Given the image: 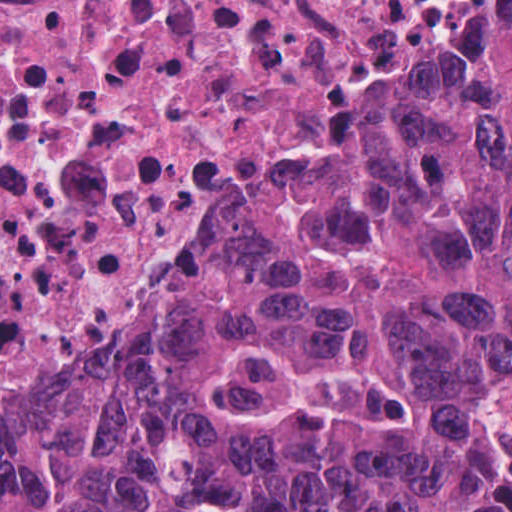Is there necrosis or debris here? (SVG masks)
Segmentation results:
<instances>
[{"label":"necrosis or debris","instance_id":"necrosis-or-debris-1","mask_svg":"<svg viewBox=\"0 0 512 512\" xmlns=\"http://www.w3.org/2000/svg\"><path fill=\"white\" fill-rule=\"evenodd\" d=\"M512 0H0V419Z\"/></svg>","mask_w":512,"mask_h":512}]
</instances>
